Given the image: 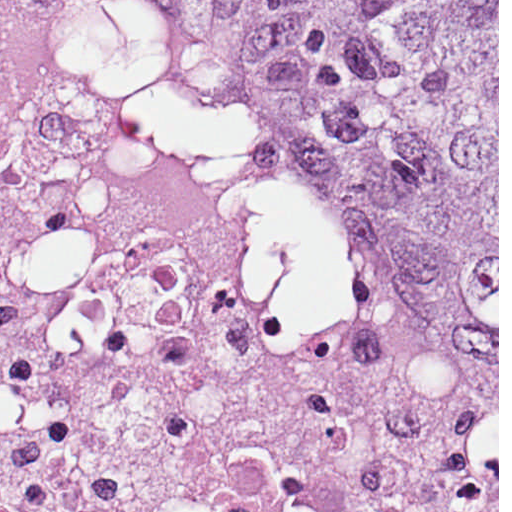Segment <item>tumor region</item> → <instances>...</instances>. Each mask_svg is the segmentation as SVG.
<instances>
[{
    "label": "tumor region",
    "instance_id": "e687c5a6",
    "mask_svg": "<svg viewBox=\"0 0 512 512\" xmlns=\"http://www.w3.org/2000/svg\"><path fill=\"white\" fill-rule=\"evenodd\" d=\"M309 287L431 416L497 408V0H152Z\"/></svg>",
    "mask_w": 512,
    "mask_h": 512
}]
</instances>
